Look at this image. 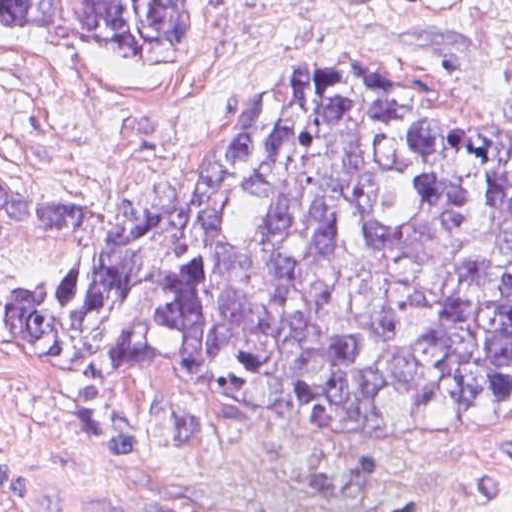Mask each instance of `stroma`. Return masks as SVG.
I'll use <instances>...</instances> for the list:
<instances>
[{
    "instance_id": "stroma-1",
    "label": "stroma",
    "mask_w": 512,
    "mask_h": 512,
    "mask_svg": "<svg viewBox=\"0 0 512 512\" xmlns=\"http://www.w3.org/2000/svg\"><path fill=\"white\" fill-rule=\"evenodd\" d=\"M188 49L140 65L0 22V170L117 215L308 72L371 74L512 136V0H190ZM70 241L0 224V512H512V408L328 439L232 417L170 362H26L9 288Z\"/></svg>"
}]
</instances>
